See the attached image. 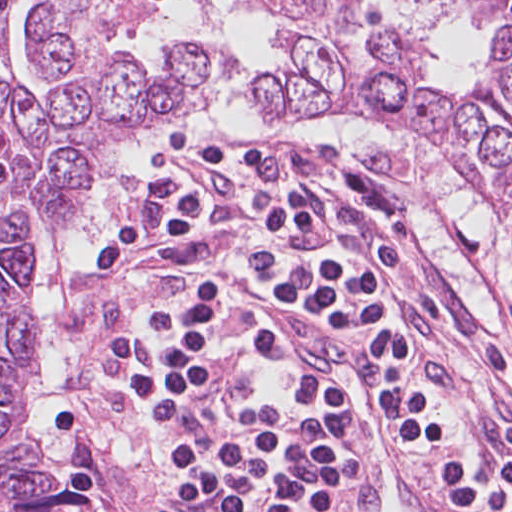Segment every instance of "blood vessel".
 <instances>
[{
	"label": "blood vessel",
	"instance_id": "blood-vessel-1",
	"mask_svg": "<svg viewBox=\"0 0 512 512\" xmlns=\"http://www.w3.org/2000/svg\"><path fill=\"white\" fill-rule=\"evenodd\" d=\"M268 300L256 309L261 327L294 359L349 432L360 466L358 512H445L384 418L369 342L282 298Z\"/></svg>",
	"mask_w": 512,
	"mask_h": 512
}]
</instances>
